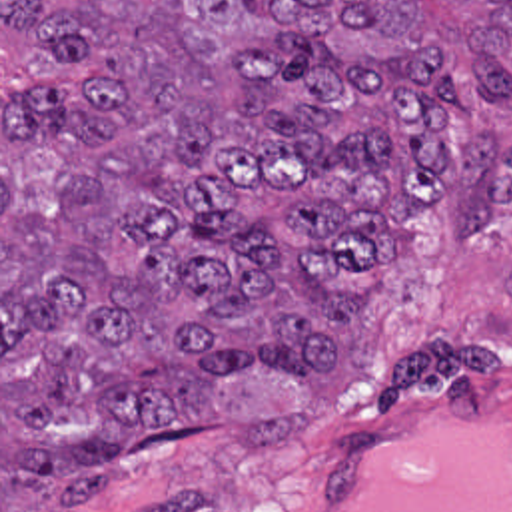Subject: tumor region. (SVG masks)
<instances>
[{
    "label": "tumor region",
    "mask_w": 512,
    "mask_h": 512,
    "mask_svg": "<svg viewBox=\"0 0 512 512\" xmlns=\"http://www.w3.org/2000/svg\"><path fill=\"white\" fill-rule=\"evenodd\" d=\"M512 0H0V492L256 444L443 215L487 241Z\"/></svg>",
    "instance_id": "tumor-region-1"
}]
</instances>
